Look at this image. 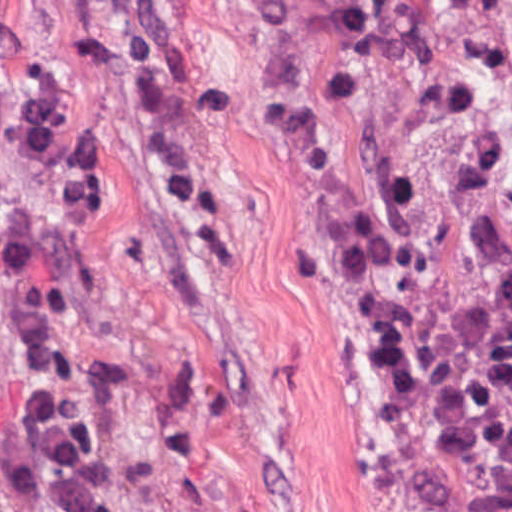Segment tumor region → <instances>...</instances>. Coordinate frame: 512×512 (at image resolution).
Instances as JSON below:
<instances>
[{
    "label": "tumor region",
    "mask_w": 512,
    "mask_h": 512,
    "mask_svg": "<svg viewBox=\"0 0 512 512\" xmlns=\"http://www.w3.org/2000/svg\"><path fill=\"white\" fill-rule=\"evenodd\" d=\"M195 286L251 266L224 0H52ZM335 181L391 512H512V199L461 0H278Z\"/></svg>",
    "instance_id": "1"
}]
</instances>
